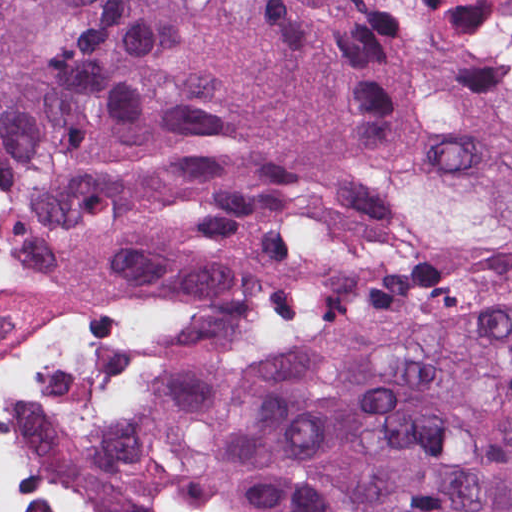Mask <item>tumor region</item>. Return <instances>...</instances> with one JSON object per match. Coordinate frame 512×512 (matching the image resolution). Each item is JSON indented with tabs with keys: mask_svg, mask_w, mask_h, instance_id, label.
I'll return each instance as SVG.
<instances>
[{
	"mask_svg": "<svg viewBox=\"0 0 512 512\" xmlns=\"http://www.w3.org/2000/svg\"><path fill=\"white\" fill-rule=\"evenodd\" d=\"M0 282L122 512H512V0H0Z\"/></svg>",
	"mask_w": 512,
	"mask_h": 512,
	"instance_id": "tumor-region-1",
	"label": "tumor region"
}]
</instances>
